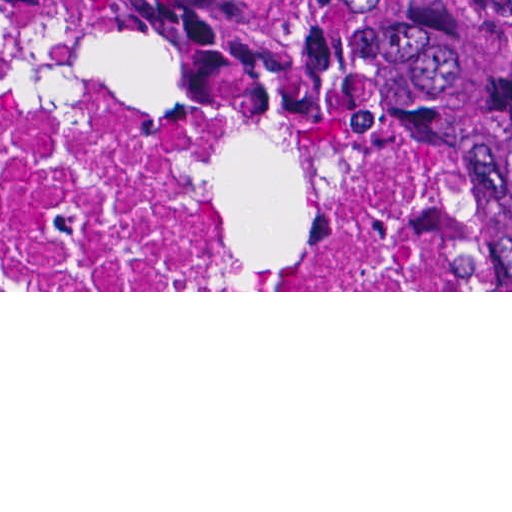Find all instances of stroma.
I'll list each match as a JSON object with an SVG mask.
<instances>
[{"mask_svg": "<svg viewBox=\"0 0 512 512\" xmlns=\"http://www.w3.org/2000/svg\"><path fill=\"white\" fill-rule=\"evenodd\" d=\"M0 19L204 81L287 96L336 117L387 127L445 171L485 238L475 290H0V292H512V113H392L278 82L238 50L70 7L0 0Z\"/></svg>", "mask_w": 512, "mask_h": 512, "instance_id": "1", "label": "stroma"}]
</instances>
